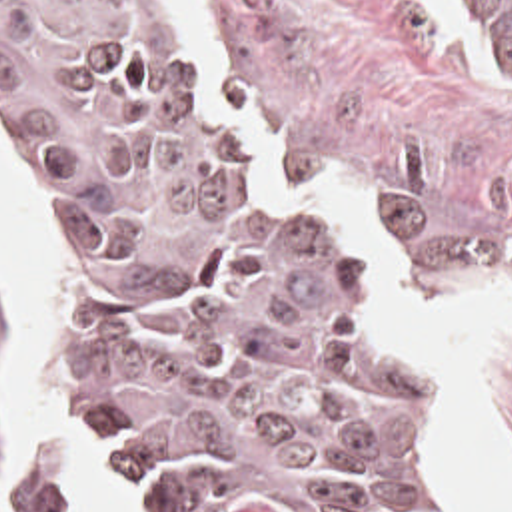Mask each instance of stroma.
Returning a JSON list of instances; mask_svg holds the SVG:
<instances>
[{
    "instance_id": "1",
    "label": "stroma",
    "mask_w": 512,
    "mask_h": 512,
    "mask_svg": "<svg viewBox=\"0 0 512 512\" xmlns=\"http://www.w3.org/2000/svg\"><path fill=\"white\" fill-rule=\"evenodd\" d=\"M262 147L288 167L302 199L384 283L456 446L448 390L416 342V327L324 183L356 195L408 291L420 297L494 295L512 285V37L486 15L494 65L474 59L430 0H176ZM0 161L34 203L50 239V283L62 247L56 217L0 135ZM20 332L0 287V482L12 452L6 372ZM46 338L56 406L108 476L110 456L88 436L62 394V366ZM480 366L512 448V332L484 342ZM458 454V448H456ZM460 462V458H458ZM64 466L40 454L0 512H66ZM470 512H482L460 464ZM122 512H126L122 498Z\"/></svg>"
}]
</instances>
